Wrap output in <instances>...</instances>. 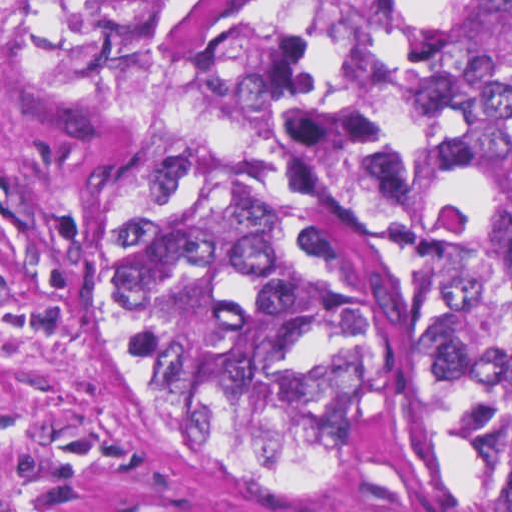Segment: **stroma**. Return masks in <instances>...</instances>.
<instances>
[{
	"mask_svg": "<svg viewBox=\"0 0 512 512\" xmlns=\"http://www.w3.org/2000/svg\"><path fill=\"white\" fill-rule=\"evenodd\" d=\"M332 0H201L195 58L218 121L282 192L293 116ZM131 161L0 58V512H351L268 489L119 364L113 280ZM463 512L512 489L457 469Z\"/></svg>",
	"mask_w": 512,
	"mask_h": 512,
	"instance_id": "obj_1",
	"label": "stroma"
}]
</instances>
